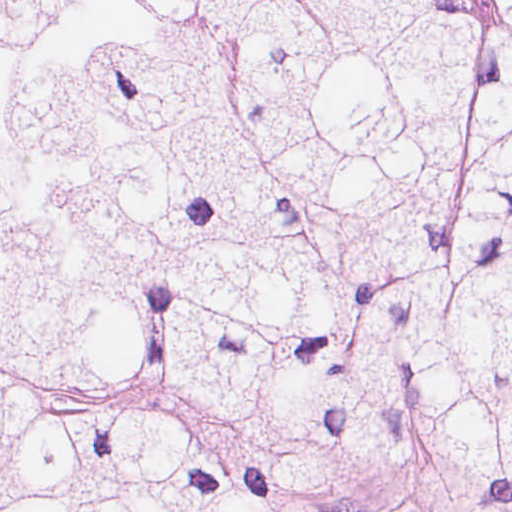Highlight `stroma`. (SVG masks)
<instances>
[{"label":"stroma","mask_w":512,"mask_h":512,"mask_svg":"<svg viewBox=\"0 0 512 512\" xmlns=\"http://www.w3.org/2000/svg\"><path fill=\"white\" fill-rule=\"evenodd\" d=\"M0 1H512V0H0ZM324 512H431L427 505L367 484L327 488Z\"/></svg>","instance_id":"35a3bbf8"}]
</instances>
